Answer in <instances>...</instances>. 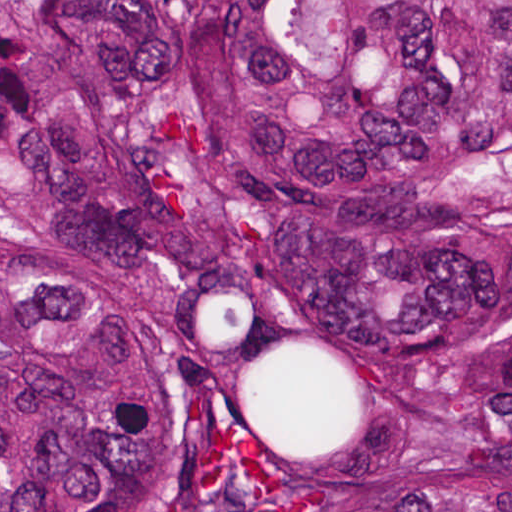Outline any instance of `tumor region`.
Segmentation results:
<instances>
[{
  "label": "tumor region",
  "instance_id": "e687c5a6",
  "mask_svg": "<svg viewBox=\"0 0 512 512\" xmlns=\"http://www.w3.org/2000/svg\"><path fill=\"white\" fill-rule=\"evenodd\" d=\"M0 512H512V0H0Z\"/></svg>",
  "mask_w": 512,
  "mask_h": 512
}]
</instances>
